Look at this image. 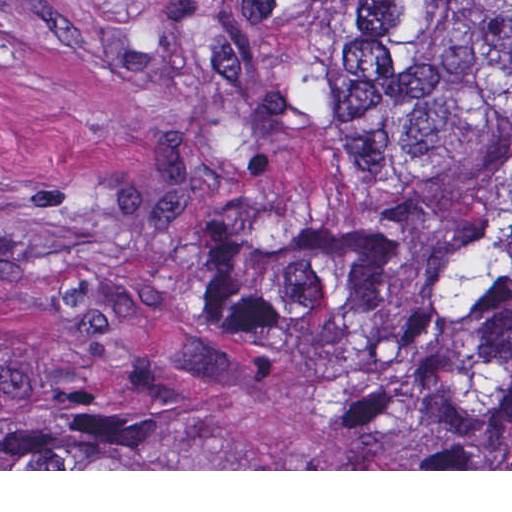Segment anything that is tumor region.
<instances>
[{"mask_svg":"<svg viewBox=\"0 0 512 512\" xmlns=\"http://www.w3.org/2000/svg\"><path fill=\"white\" fill-rule=\"evenodd\" d=\"M253 213L191 286L248 344L366 370L428 435L512 430V0H205ZM125 411L0 392V469H130Z\"/></svg>","mask_w":512,"mask_h":512,"instance_id":"obj_1","label":"tumor region"}]
</instances>
